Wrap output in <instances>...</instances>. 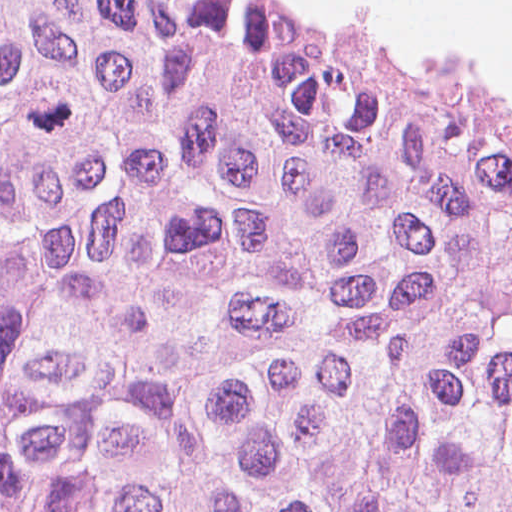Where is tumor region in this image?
I'll return each mask as SVG.
<instances>
[{
    "instance_id": "obj_1",
    "label": "tumor region",
    "mask_w": 512,
    "mask_h": 512,
    "mask_svg": "<svg viewBox=\"0 0 512 512\" xmlns=\"http://www.w3.org/2000/svg\"><path fill=\"white\" fill-rule=\"evenodd\" d=\"M0 512H512V119L290 0H0Z\"/></svg>"
}]
</instances>
